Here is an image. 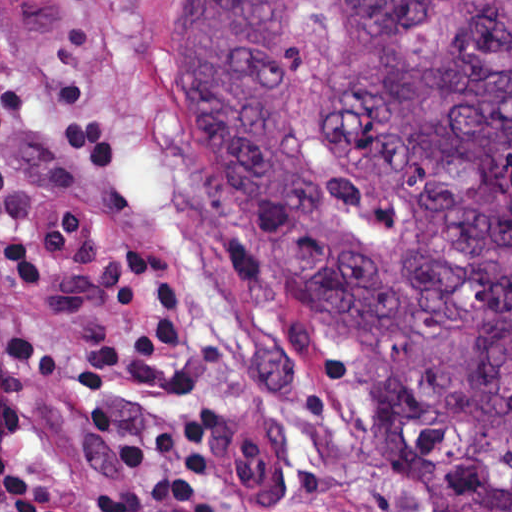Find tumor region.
<instances>
[{"label":"tumor region","instance_id":"e687c5a6","mask_svg":"<svg viewBox=\"0 0 512 512\" xmlns=\"http://www.w3.org/2000/svg\"><path fill=\"white\" fill-rule=\"evenodd\" d=\"M260 272L390 369L422 512H512V0H158Z\"/></svg>","mask_w":512,"mask_h":512}]
</instances>
